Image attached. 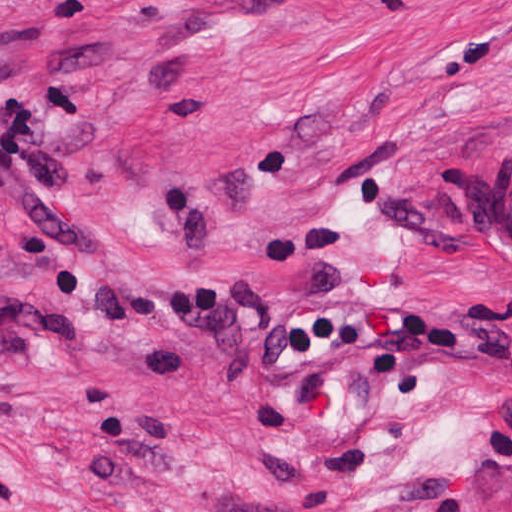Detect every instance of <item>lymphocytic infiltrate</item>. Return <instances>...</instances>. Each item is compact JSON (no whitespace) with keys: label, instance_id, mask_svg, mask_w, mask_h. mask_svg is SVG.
Instances as JSON below:
<instances>
[{"label":"lymphocytic infiltrate","instance_id":"lymphocytic-infiltrate-1","mask_svg":"<svg viewBox=\"0 0 512 512\" xmlns=\"http://www.w3.org/2000/svg\"><path fill=\"white\" fill-rule=\"evenodd\" d=\"M153 47L149 32L104 34L45 60L0 47V216L52 260H102L122 246L73 194L70 113L94 100V74L134 68Z\"/></svg>","mask_w":512,"mask_h":512}]
</instances>
